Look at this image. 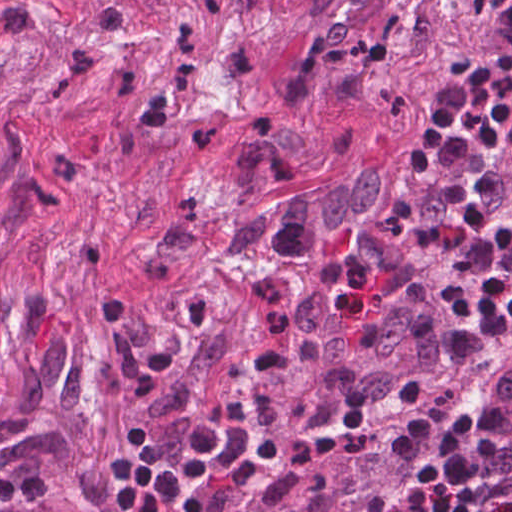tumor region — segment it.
<instances>
[{"instance_id":"e687c5a6","label":"tumor region","mask_w":512,"mask_h":512,"mask_svg":"<svg viewBox=\"0 0 512 512\" xmlns=\"http://www.w3.org/2000/svg\"><path fill=\"white\" fill-rule=\"evenodd\" d=\"M411 428L400 419L306 438L188 477L175 512H426L431 483L394 465Z\"/></svg>"}]
</instances>
